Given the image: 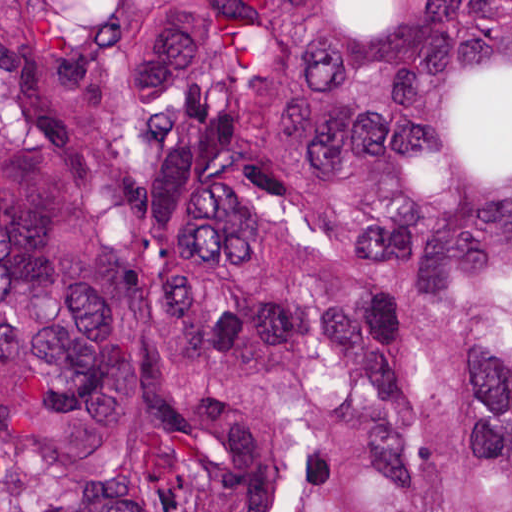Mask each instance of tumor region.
Listing matches in <instances>:
<instances>
[{
    "label": "tumor region",
    "mask_w": 512,
    "mask_h": 512,
    "mask_svg": "<svg viewBox=\"0 0 512 512\" xmlns=\"http://www.w3.org/2000/svg\"><path fill=\"white\" fill-rule=\"evenodd\" d=\"M0 512H512V0H0Z\"/></svg>",
    "instance_id": "1"
}]
</instances>
